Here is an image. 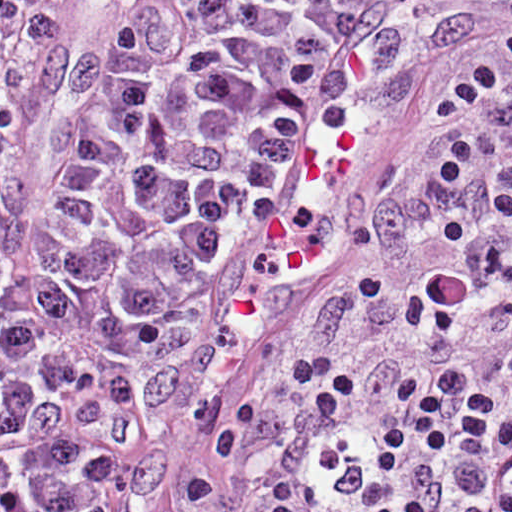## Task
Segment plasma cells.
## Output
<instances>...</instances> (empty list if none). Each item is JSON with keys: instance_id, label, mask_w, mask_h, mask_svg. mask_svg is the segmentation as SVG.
<instances>
[{"instance_id": "obj_1", "label": "plasma cells", "mask_w": 512, "mask_h": 512, "mask_svg": "<svg viewBox=\"0 0 512 512\" xmlns=\"http://www.w3.org/2000/svg\"><path fill=\"white\" fill-rule=\"evenodd\" d=\"M343 10L0 0V512H98L126 405Z\"/></svg>"}]
</instances>
